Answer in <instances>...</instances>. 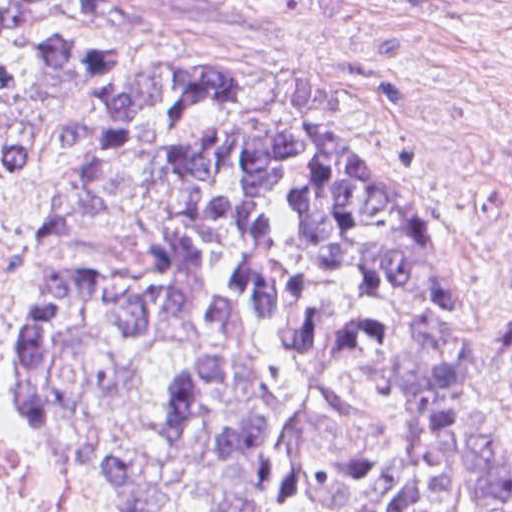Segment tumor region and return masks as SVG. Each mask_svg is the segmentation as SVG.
Here are the masks:
<instances>
[{
	"label": "tumor region",
	"mask_w": 512,
	"mask_h": 512,
	"mask_svg": "<svg viewBox=\"0 0 512 512\" xmlns=\"http://www.w3.org/2000/svg\"><path fill=\"white\" fill-rule=\"evenodd\" d=\"M34 3L0 1V167L74 94L66 177L41 226L0 210V264L31 283L17 405L50 462L132 512H512L503 386L460 491L461 295L429 216L349 138Z\"/></svg>",
	"instance_id": "obj_1"
}]
</instances>
